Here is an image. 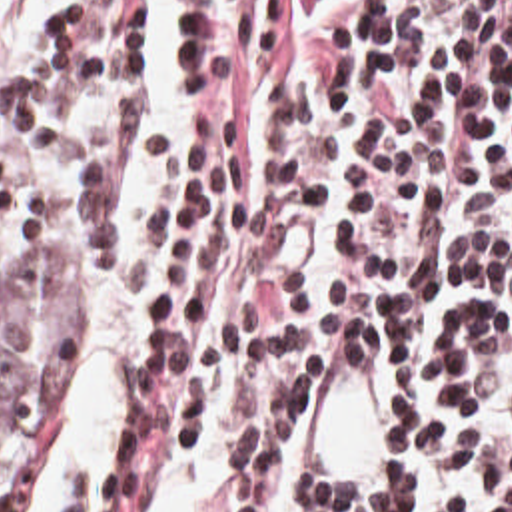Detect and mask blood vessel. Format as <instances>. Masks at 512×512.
Here are the masks:
<instances>
[{
  "label": "blood vessel",
  "mask_w": 512,
  "mask_h": 512,
  "mask_svg": "<svg viewBox=\"0 0 512 512\" xmlns=\"http://www.w3.org/2000/svg\"><path fill=\"white\" fill-rule=\"evenodd\" d=\"M394 460V391L364 323L312 379L300 409V478L312 494H356Z\"/></svg>",
  "instance_id": "8fb6f2fc"
}]
</instances>
